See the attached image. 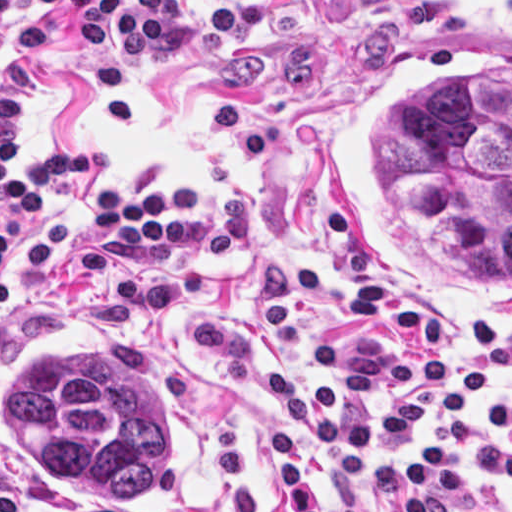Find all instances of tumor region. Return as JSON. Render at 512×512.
Here are the masks:
<instances>
[{"label": "tumor region", "mask_w": 512, "mask_h": 512, "mask_svg": "<svg viewBox=\"0 0 512 512\" xmlns=\"http://www.w3.org/2000/svg\"><path fill=\"white\" fill-rule=\"evenodd\" d=\"M17 443L78 492L138 502L162 485V421L139 370L104 352L55 345L3 390Z\"/></svg>", "instance_id": "obj_1"}]
</instances>
